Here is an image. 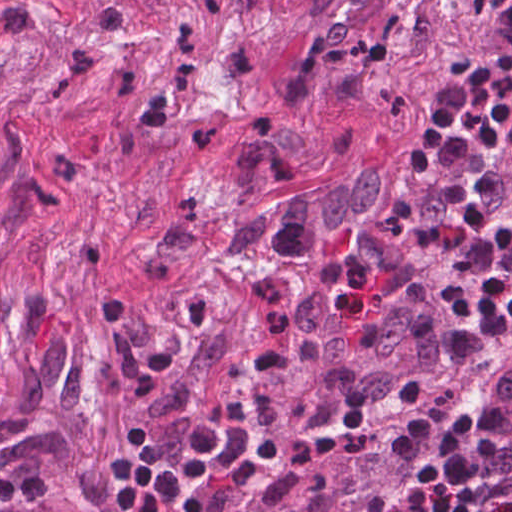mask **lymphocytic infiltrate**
<instances>
[{
    "label": "lymphocytic infiltrate",
    "mask_w": 512,
    "mask_h": 512,
    "mask_svg": "<svg viewBox=\"0 0 512 512\" xmlns=\"http://www.w3.org/2000/svg\"><path fill=\"white\" fill-rule=\"evenodd\" d=\"M512 325V117L310 340L342 413L409 406L394 465L431 483L426 512H512L501 480L503 417L437 394ZM323 436L263 393L188 477L246 465ZM177 488L157 512H175Z\"/></svg>",
    "instance_id": "f902f5d3"
}]
</instances>
